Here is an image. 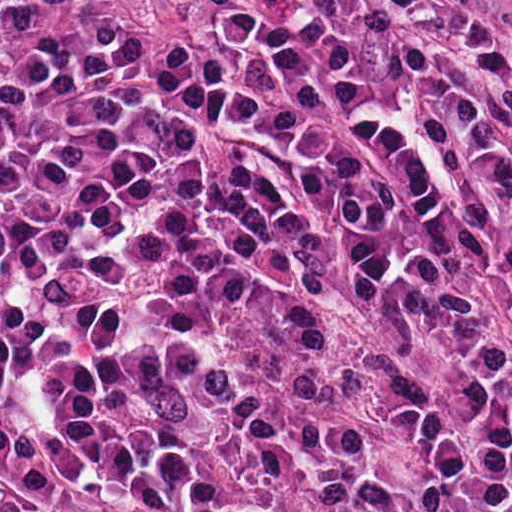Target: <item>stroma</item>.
Wrapping results in <instances>:
<instances>
[{
  "instance_id": "stroma-1",
  "label": "stroma",
  "mask_w": 512,
  "mask_h": 512,
  "mask_svg": "<svg viewBox=\"0 0 512 512\" xmlns=\"http://www.w3.org/2000/svg\"><path fill=\"white\" fill-rule=\"evenodd\" d=\"M507 60L512 67V0H507ZM0 433L44 440L110 492L147 507L182 512L149 464L111 442L82 411L6 404L1 368Z\"/></svg>"
}]
</instances>
